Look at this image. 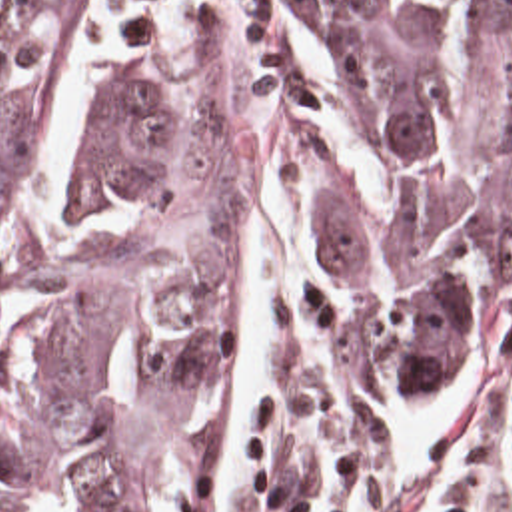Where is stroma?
Returning <instances> with one entry per match:
<instances>
[{
    "label": "stroma",
    "instance_id": "stroma-1",
    "mask_svg": "<svg viewBox=\"0 0 512 512\" xmlns=\"http://www.w3.org/2000/svg\"><path fill=\"white\" fill-rule=\"evenodd\" d=\"M125 27L123 61L213 109L231 139V289L219 309L207 446L181 512H209L227 420L235 323V217L251 175L275 173L317 209V287L283 315L273 396L227 512H315L349 440L431 422L512 388V279L493 297L481 364L443 390H375L345 321L341 277L325 241L319 151L307 109L279 81L267 0H77Z\"/></svg>",
    "mask_w": 512,
    "mask_h": 512
}]
</instances>
